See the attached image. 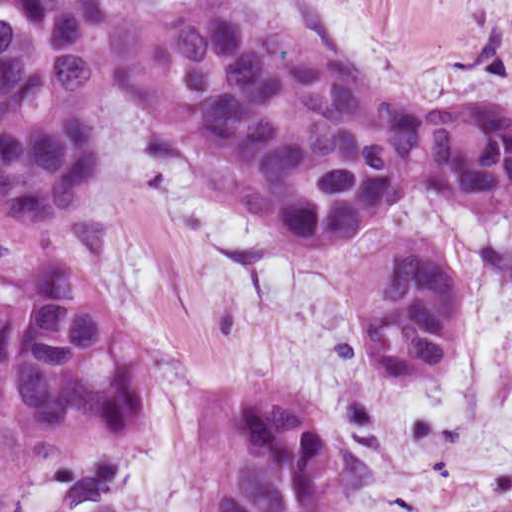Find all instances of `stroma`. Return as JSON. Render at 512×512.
<instances>
[{
    "label": "stroma",
    "mask_w": 512,
    "mask_h": 512,
    "mask_svg": "<svg viewBox=\"0 0 512 512\" xmlns=\"http://www.w3.org/2000/svg\"><path fill=\"white\" fill-rule=\"evenodd\" d=\"M139 11L200 0H120ZM351 57L387 91L434 106L512 104V0H242ZM102 167L56 222L0 223V269L81 266L146 342V436L172 469L182 418L219 387H299L359 448L368 512H478L512 454V219L466 216L428 188L360 235L299 243L196 161L163 104L120 87L99 116ZM472 277L460 352L421 383H383L359 328L357 275L396 237Z\"/></svg>",
    "instance_id": "35a3bbf8"
}]
</instances>
